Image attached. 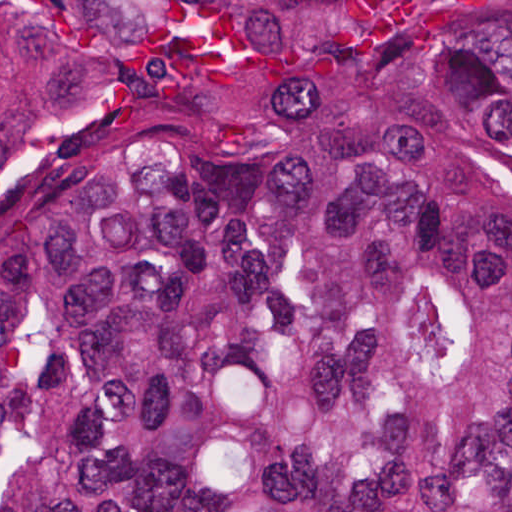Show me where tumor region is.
Masks as SVG:
<instances>
[{
	"instance_id": "e687c5a6",
	"label": "tumor region",
	"mask_w": 512,
	"mask_h": 512,
	"mask_svg": "<svg viewBox=\"0 0 512 512\" xmlns=\"http://www.w3.org/2000/svg\"><path fill=\"white\" fill-rule=\"evenodd\" d=\"M1 512H512V0H1Z\"/></svg>"
}]
</instances>
